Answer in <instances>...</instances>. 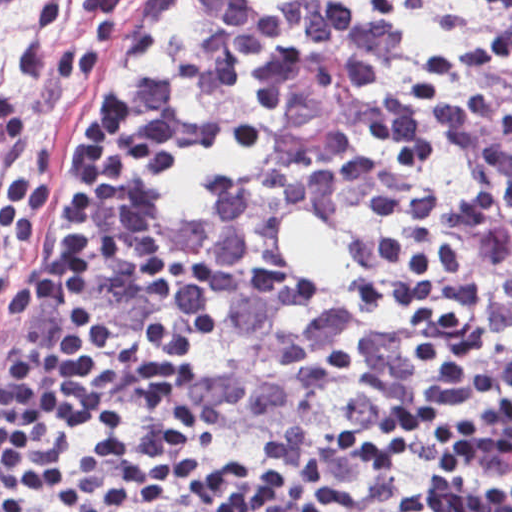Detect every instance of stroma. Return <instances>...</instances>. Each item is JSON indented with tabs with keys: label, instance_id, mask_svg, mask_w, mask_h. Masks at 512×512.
Returning <instances> with one entry per match:
<instances>
[{
	"label": "stroma",
	"instance_id": "35a3bbf8",
	"mask_svg": "<svg viewBox=\"0 0 512 512\" xmlns=\"http://www.w3.org/2000/svg\"><path fill=\"white\" fill-rule=\"evenodd\" d=\"M111 1H512V0H0V174L32 168L51 182V200L33 218L31 251L0 234V379L17 351L57 360L76 346L104 361L111 387V335L132 265L129 148L117 103V141L98 191L91 260V313L103 335L87 338L67 307L47 295L44 268L67 215V143L111 84ZM84 430L37 445L0 488V512H21L64 450Z\"/></svg>",
	"mask_w": 512,
	"mask_h": 512
}]
</instances>
